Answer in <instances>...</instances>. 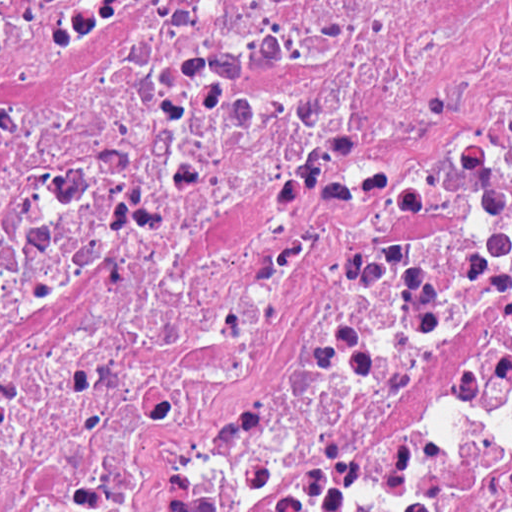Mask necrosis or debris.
Segmentation results:
<instances>
[{"label": "necrosis or debris", "instance_id": "necrosis-or-debris-1", "mask_svg": "<svg viewBox=\"0 0 512 512\" xmlns=\"http://www.w3.org/2000/svg\"><path fill=\"white\" fill-rule=\"evenodd\" d=\"M0 512H512V0H0Z\"/></svg>", "mask_w": 512, "mask_h": 512}]
</instances>
